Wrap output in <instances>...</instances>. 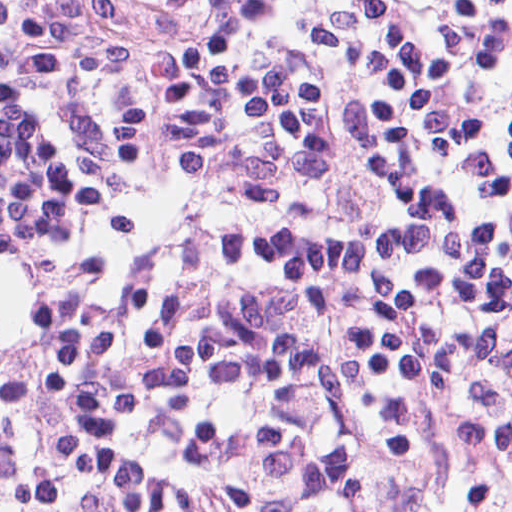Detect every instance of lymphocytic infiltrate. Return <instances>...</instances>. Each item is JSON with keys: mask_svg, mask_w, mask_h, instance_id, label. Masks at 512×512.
Instances as JSON below:
<instances>
[{"mask_svg": "<svg viewBox=\"0 0 512 512\" xmlns=\"http://www.w3.org/2000/svg\"><path fill=\"white\" fill-rule=\"evenodd\" d=\"M512 354V0H0V512H412Z\"/></svg>", "mask_w": 512, "mask_h": 512, "instance_id": "f902f5d3", "label": "lymphocytic infiltrate"}]
</instances>
